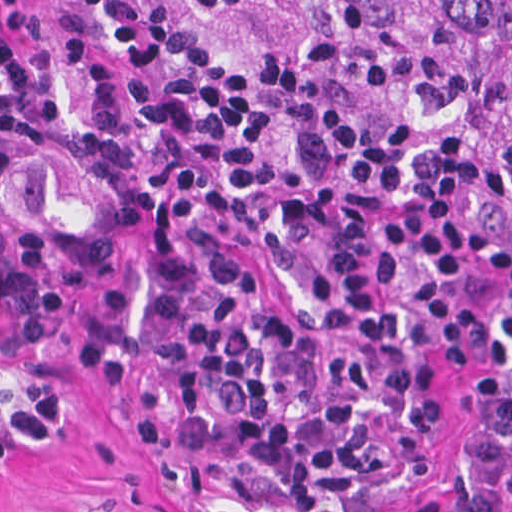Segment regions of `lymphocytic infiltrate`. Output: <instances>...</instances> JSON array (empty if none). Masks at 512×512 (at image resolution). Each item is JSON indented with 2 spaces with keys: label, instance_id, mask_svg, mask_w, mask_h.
Wrapping results in <instances>:
<instances>
[{
  "label": "lymphocytic infiltrate",
  "instance_id": "1",
  "mask_svg": "<svg viewBox=\"0 0 512 512\" xmlns=\"http://www.w3.org/2000/svg\"><path fill=\"white\" fill-rule=\"evenodd\" d=\"M511 219L466 142L279 100L175 0H0V292L145 255L124 416L198 511L431 476Z\"/></svg>",
  "mask_w": 512,
  "mask_h": 512
}]
</instances>
